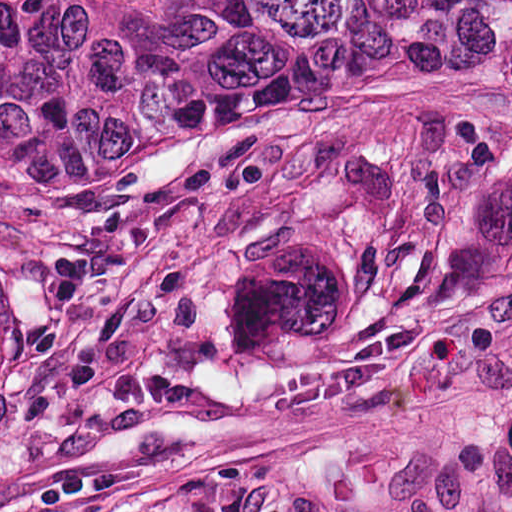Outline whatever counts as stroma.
<instances>
[{
  "mask_svg": "<svg viewBox=\"0 0 512 512\" xmlns=\"http://www.w3.org/2000/svg\"><path fill=\"white\" fill-rule=\"evenodd\" d=\"M0 512H512V270L0 105Z\"/></svg>",
  "mask_w": 512,
  "mask_h": 512,
  "instance_id": "35a3bbf8",
  "label": "stroma"
}]
</instances>
